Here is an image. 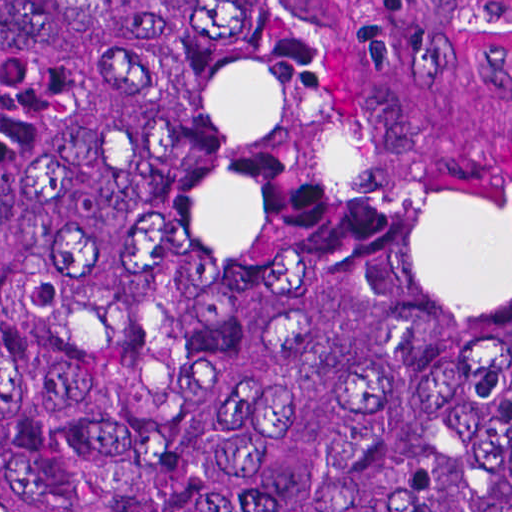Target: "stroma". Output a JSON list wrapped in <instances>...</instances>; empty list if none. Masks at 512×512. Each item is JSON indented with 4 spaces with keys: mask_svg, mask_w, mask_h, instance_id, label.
Segmentation results:
<instances>
[{
    "mask_svg": "<svg viewBox=\"0 0 512 512\" xmlns=\"http://www.w3.org/2000/svg\"><path fill=\"white\" fill-rule=\"evenodd\" d=\"M477 132L512 156V0H362Z\"/></svg>",
    "mask_w": 512,
    "mask_h": 512,
    "instance_id": "obj_1",
    "label": "stroma"
}]
</instances>
